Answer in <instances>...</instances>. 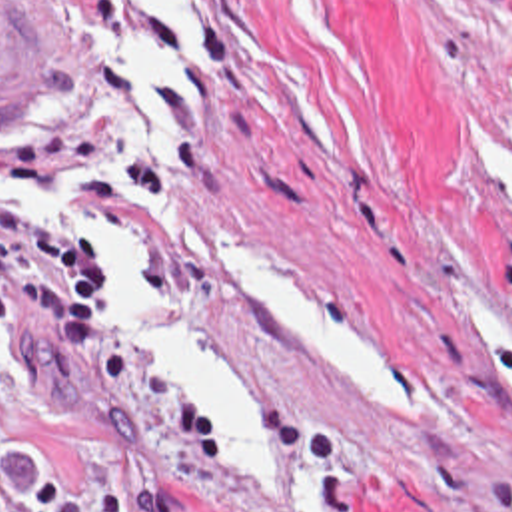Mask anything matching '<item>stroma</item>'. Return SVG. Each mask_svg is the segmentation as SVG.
<instances>
[{"mask_svg":"<svg viewBox=\"0 0 512 512\" xmlns=\"http://www.w3.org/2000/svg\"><path fill=\"white\" fill-rule=\"evenodd\" d=\"M53 56V100L0 124V208L101 268V345L69 355L25 309L0 335V461L9 497L57 479L89 512H299L309 449L339 512H512V226L475 176L471 136L512 138V0H185L209 50L203 128L177 116V170L113 92V34L81 0H3ZM125 140L193 236L67 190L137 252L149 283L223 361L271 455V485L209 451L175 389L117 337L93 238L19 202ZM235 240L347 307L409 369L419 417L357 403L269 329L221 274Z\"/></svg>","mask_w":512,"mask_h":512,"instance_id":"stroma-1","label":"stroma"}]
</instances>
